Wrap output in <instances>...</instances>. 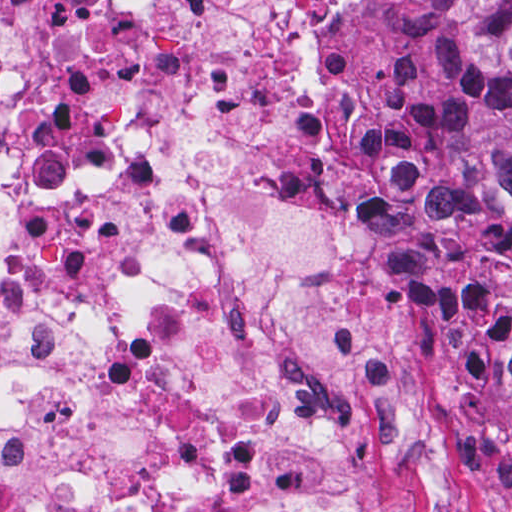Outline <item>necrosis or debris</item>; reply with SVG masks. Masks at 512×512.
I'll return each mask as SVG.
<instances>
[{
	"mask_svg": "<svg viewBox=\"0 0 512 512\" xmlns=\"http://www.w3.org/2000/svg\"><path fill=\"white\" fill-rule=\"evenodd\" d=\"M457 95L432 0H0V512L486 504Z\"/></svg>",
	"mask_w": 512,
	"mask_h": 512,
	"instance_id": "obj_1",
	"label": "necrosis or debris"
}]
</instances>
